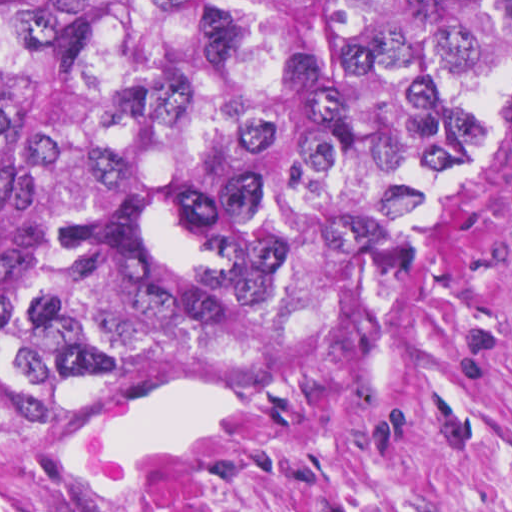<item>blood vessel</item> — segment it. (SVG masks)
I'll use <instances>...</instances> for the list:
<instances>
[{
    "instance_id": "8fb6f2fc",
    "label": "blood vessel",
    "mask_w": 512,
    "mask_h": 512,
    "mask_svg": "<svg viewBox=\"0 0 512 512\" xmlns=\"http://www.w3.org/2000/svg\"><path fill=\"white\" fill-rule=\"evenodd\" d=\"M255 381L161 377L38 436L34 471L60 512H176L240 452Z\"/></svg>"
}]
</instances>
